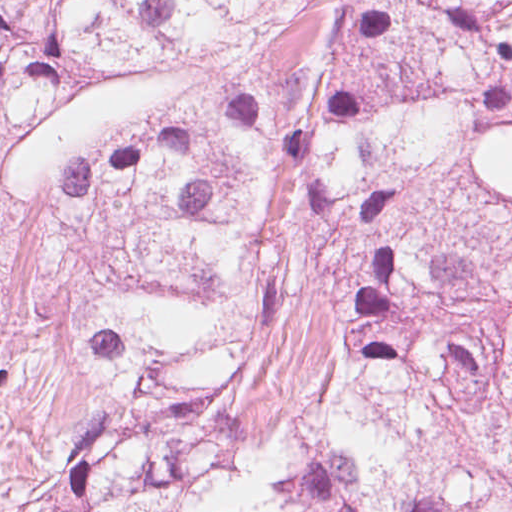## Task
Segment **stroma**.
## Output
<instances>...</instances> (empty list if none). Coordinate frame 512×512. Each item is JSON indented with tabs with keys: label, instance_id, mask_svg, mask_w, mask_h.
Segmentation results:
<instances>
[{
	"label": "stroma",
	"instance_id": "1",
	"mask_svg": "<svg viewBox=\"0 0 512 512\" xmlns=\"http://www.w3.org/2000/svg\"><path fill=\"white\" fill-rule=\"evenodd\" d=\"M119 148L10 110L0 116V512H34L104 405L82 352L94 262L63 189L87 159ZM319 215L267 199L238 379L219 419L234 441L278 429L319 358Z\"/></svg>",
	"mask_w": 512,
	"mask_h": 512
}]
</instances>
